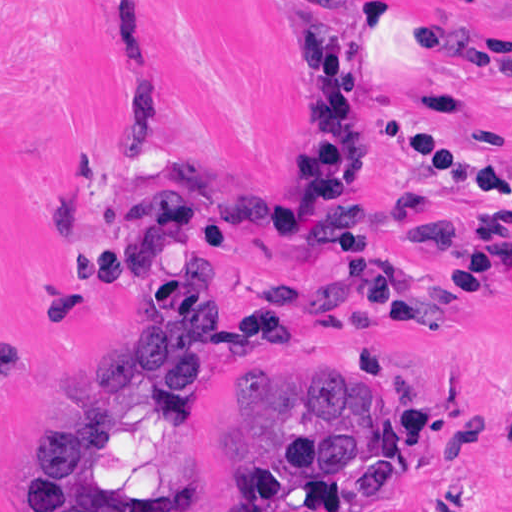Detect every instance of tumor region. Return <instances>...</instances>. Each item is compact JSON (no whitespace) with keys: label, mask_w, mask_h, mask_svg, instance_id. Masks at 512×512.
I'll return each mask as SVG.
<instances>
[{"label":"tumor region","mask_w":512,"mask_h":512,"mask_svg":"<svg viewBox=\"0 0 512 512\" xmlns=\"http://www.w3.org/2000/svg\"><path fill=\"white\" fill-rule=\"evenodd\" d=\"M220 339L217 290L164 323H111L99 353L97 341L104 382L93 411L85 419L48 417L33 429L28 511L132 509L126 492L109 487L93 488L79 505L63 492L70 475L96 468L121 440L116 396L131 375L150 377L160 393L188 394L205 384ZM389 441L365 376L325 366L289 378L277 361L255 359L238 371V394L206 440L238 462L234 489L210 512H339L344 498L397 500L399 461Z\"/></svg>","instance_id":"obj_1"}]
</instances>
